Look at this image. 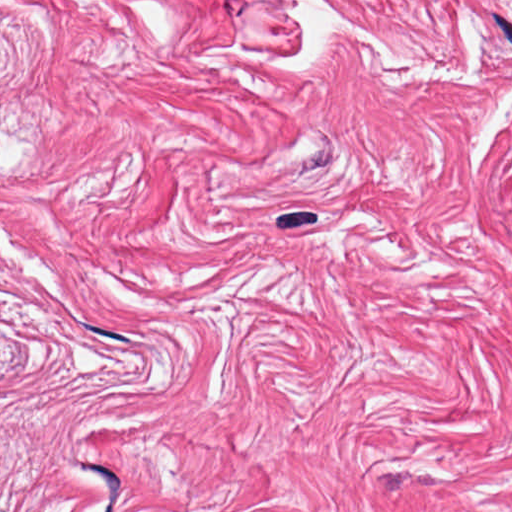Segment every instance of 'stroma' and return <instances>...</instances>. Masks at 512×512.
Here are the masks:
<instances>
[{"label":"stroma","mask_w":512,"mask_h":512,"mask_svg":"<svg viewBox=\"0 0 512 512\" xmlns=\"http://www.w3.org/2000/svg\"><path fill=\"white\" fill-rule=\"evenodd\" d=\"M0 512H512V140L0 87Z\"/></svg>","instance_id":"1"}]
</instances>
